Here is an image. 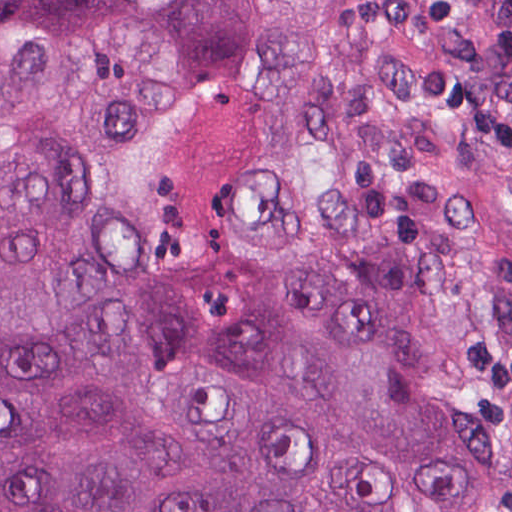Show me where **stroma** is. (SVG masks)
Here are the masks:
<instances>
[{
  "mask_svg": "<svg viewBox=\"0 0 512 512\" xmlns=\"http://www.w3.org/2000/svg\"><path fill=\"white\" fill-rule=\"evenodd\" d=\"M437 344H438V342H437ZM436 348H437V346H436ZM435 353H436V350H435ZM434 357H435V354H434ZM433 362H434V358H433ZM433 362H432V366H433ZM432 366H431V370H430V374H429V378H428V382H427V386H426V390H425V394H424V398H423V402H422V406H421L418 422H417V427H416V430H415V434H414V438H413V442H412V446H411V450H410V454H409V458H408V462H407V466H406V470H405V474H404V478H403V482H402V486H401V490H400V494H399V498H398V502H397V506H396L395 512H400L401 511V506H402V502H403V497H404L405 488H406V484H407V479H408V475H409L410 465H411V461H412V456H413V452H414L416 438H417V434H418V430H419V425H420L421 416H422V412H423V407H424V403H425V398H426V394H427V389H428V385H429V380H430V375H431V371H432Z\"/></svg>",
  "mask_w": 512,
  "mask_h": 512,
  "instance_id": "obj_1",
  "label": "stroma"
}]
</instances>
